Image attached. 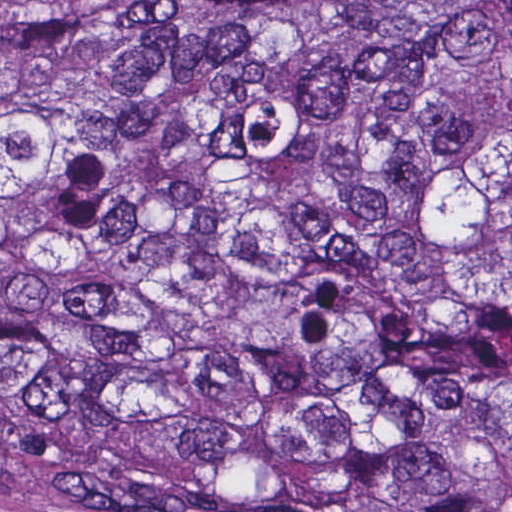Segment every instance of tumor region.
I'll list each match as a JSON object with an SVG mask.
<instances>
[{
	"label": "tumor region",
	"instance_id": "tumor-region-1",
	"mask_svg": "<svg viewBox=\"0 0 512 512\" xmlns=\"http://www.w3.org/2000/svg\"><path fill=\"white\" fill-rule=\"evenodd\" d=\"M15 464L153 512H512V0L0 34Z\"/></svg>",
	"mask_w": 512,
	"mask_h": 512
}]
</instances>
